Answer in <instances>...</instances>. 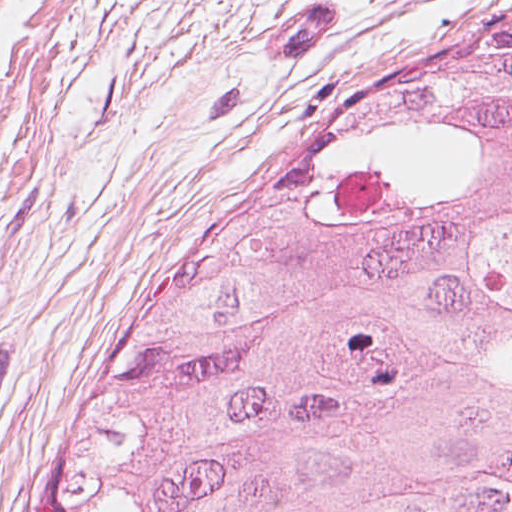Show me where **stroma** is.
<instances>
[{"label": "stroma", "instance_id": "obj_1", "mask_svg": "<svg viewBox=\"0 0 512 512\" xmlns=\"http://www.w3.org/2000/svg\"><path fill=\"white\" fill-rule=\"evenodd\" d=\"M512 0H0V512L313 132Z\"/></svg>", "mask_w": 512, "mask_h": 512}]
</instances>
